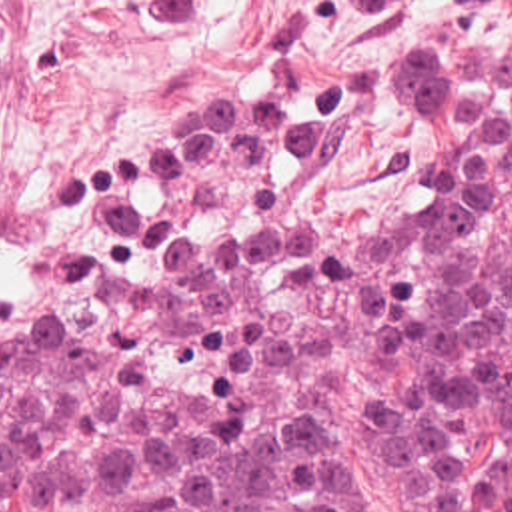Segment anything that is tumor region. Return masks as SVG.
<instances>
[{"instance_id":"obj_1","label":"tumor region","mask_w":512,"mask_h":512,"mask_svg":"<svg viewBox=\"0 0 512 512\" xmlns=\"http://www.w3.org/2000/svg\"><path fill=\"white\" fill-rule=\"evenodd\" d=\"M409 192L303 222L253 90L125 142L0 304V512H351L333 404L405 508L512 512V50L369 76Z\"/></svg>"}]
</instances>
